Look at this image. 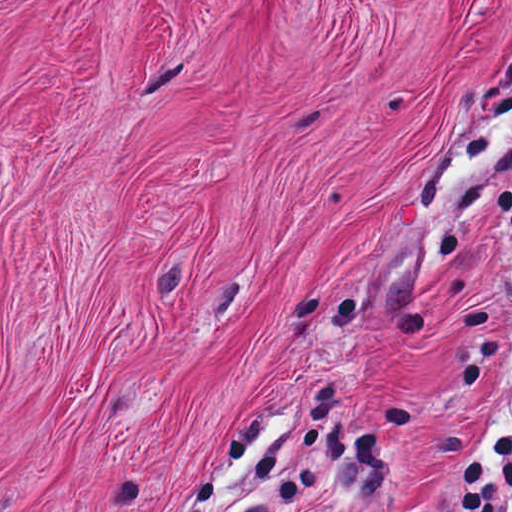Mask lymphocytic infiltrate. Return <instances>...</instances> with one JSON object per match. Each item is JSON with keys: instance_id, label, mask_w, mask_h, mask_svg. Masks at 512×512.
Returning a JSON list of instances; mask_svg holds the SVG:
<instances>
[{"instance_id": "f902f5d3", "label": "lymphocytic infiltrate", "mask_w": 512, "mask_h": 512, "mask_svg": "<svg viewBox=\"0 0 512 512\" xmlns=\"http://www.w3.org/2000/svg\"><path fill=\"white\" fill-rule=\"evenodd\" d=\"M500 59L481 109L458 149L412 179V196L423 203L455 172L482 161L479 178L453 195L442 217V253L460 238L485 192L499 223L512 234V59L496 71ZM414 512H421L420 508ZM454 512H512V433L461 460Z\"/></svg>"}]
</instances>
